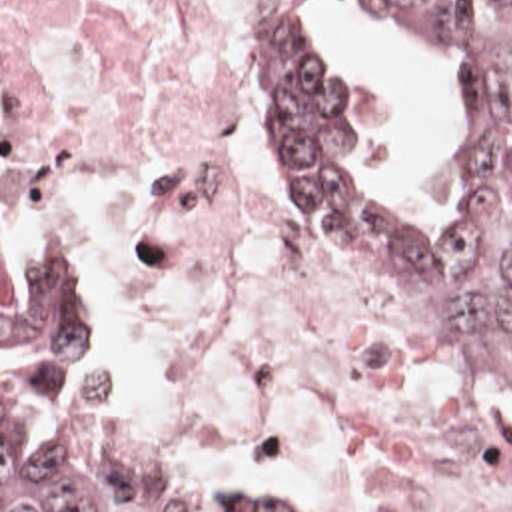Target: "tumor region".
Returning <instances> with one entry per match:
<instances>
[{"instance_id":"obj_1","label":"tumor region","mask_w":512,"mask_h":512,"mask_svg":"<svg viewBox=\"0 0 512 512\" xmlns=\"http://www.w3.org/2000/svg\"><path fill=\"white\" fill-rule=\"evenodd\" d=\"M361 1L447 77L459 117L453 209L423 235L355 207L317 121V17L300 7L274 71V151L343 257L437 323L512 399V0ZM10 349L98 361L86 291L46 243L2 253V355ZM56 379L30 359L2 385V512H302L284 497H210L136 463L100 421V383L58 415L42 445H10V427Z\"/></svg>"}]
</instances>
